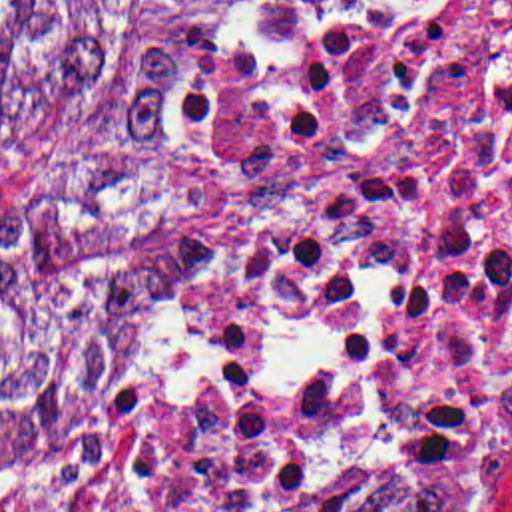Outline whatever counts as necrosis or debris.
I'll list each match as a JSON object with an SVG mask.
<instances>
[{
  "instance_id": "obj_1",
  "label": "necrosis or debris",
  "mask_w": 512,
  "mask_h": 512,
  "mask_svg": "<svg viewBox=\"0 0 512 512\" xmlns=\"http://www.w3.org/2000/svg\"><path fill=\"white\" fill-rule=\"evenodd\" d=\"M512 474V0H267L229 290L183 378L0 512L440 506Z\"/></svg>"
}]
</instances>
